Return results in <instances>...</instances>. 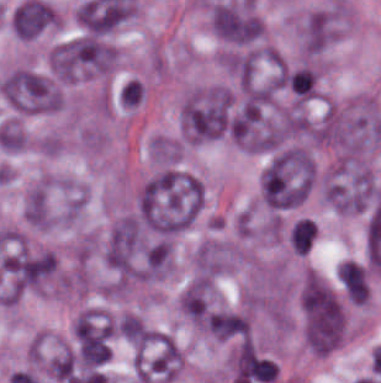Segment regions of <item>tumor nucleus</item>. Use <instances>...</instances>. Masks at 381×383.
Segmentation results:
<instances>
[{"instance_id":"3e47fb67","label":"tumor nucleus","mask_w":381,"mask_h":383,"mask_svg":"<svg viewBox=\"0 0 381 383\" xmlns=\"http://www.w3.org/2000/svg\"><path fill=\"white\" fill-rule=\"evenodd\" d=\"M315 236V224L307 219H300L290 234V246L294 252L303 256L313 243Z\"/></svg>"},{"instance_id":"feef74b5","label":"tumor nucleus","mask_w":381,"mask_h":383,"mask_svg":"<svg viewBox=\"0 0 381 383\" xmlns=\"http://www.w3.org/2000/svg\"><path fill=\"white\" fill-rule=\"evenodd\" d=\"M117 332L136 346H144L152 336L144 324L133 315H126L117 326Z\"/></svg>"},{"instance_id":"3d1891a8","label":"tumor nucleus","mask_w":381,"mask_h":383,"mask_svg":"<svg viewBox=\"0 0 381 383\" xmlns=\"http://www.w3.org/2000/svg\"><path fill=\"white\" fill-rule=\"evenodd\" d=\"M139 240L138 222L125 218L110 233L105 245L106 265L115 271L128 272Z\"/></svg>"},{"instance_id":"2cbd58db","label":"tumor nucleus","mask_w":381,"mask_h":383,"mask_svg":"<svg viewBox=\"0 0 381 383\" xmlns=\"http://www.w3.org/2000/svg\"><path fill=\"white\" fill-rule=\"evenodd\" d=\"M210 22L217 36L237 45L257 41L263 32L257 16L234 4H215Z\"/></svg>"},{"instance_id":"8087334f","label":"tumor nucleus","mask_w":381,"mask_h":383,"mask_svg":"<svg viewBox=\"0 0 381 383\" xmlns=\"http://www.w3.org/2000/svg\"><path fill=\"white\" fill-rule=\"evenodd\" d=\"M249 331V323L241 314L214 312L209 321V334L219 339H238Z\"/></svg>"},{"instance_id":"2083b535","label":"tumor nucleus","mask_w":381,"mask_h":383,"mask_svg":"<svg viewBox=\"0 0 381 383\" xmlns=\"http://www.w3.org/2000/svg\"><path fill=\"white\" fill-rule=\"evenodd\" d=\"M339 282L351 302L365 303L369 285L364 267L358 262L344 261L338 267Z\"/></svg>"},{"instance_id":"2f306a5c","label":"tumor nucleus","mask_w":381,"mask_h":383,"mask_svg":"<svg viewBox=\"0 0 381 383\" xmlns=\"http://www.w3.org/2000/svg\"><path fill=\"white\" fill-rule=\"evenodd\" d=\"M313 180V164L301 149H281L269 156L259 175L262 202L272 209L296 207Z\"/></svg>"},{"instance_id":"5ab6c2c4","label":"tumor nucleus","mask_w":381,"mask_h":383,"mask_svg":"<svg viewBox=\"0 0 381 383\" xmlns=\"http://www.w3.org/2000/svg\"><path fill=\"white\" fill-rule=\"evenodd\" d=\"M0 87L7 101L19 110L44 113L59 107V92L44 76L31 70L15 71Z\"/></svg>"},{"instance_id":"c2bd9aea","label":"tumor nucleus","mask_w":381,"mask_h":383,"mask_svg":"<svg viewBox=\"0 0 381 383\" xmlns=\"http://www.w3.org/2000/svg\"><path fill=\"white\" fill-rule=\"evenodd\" d=\"M331 34V20L324 13H311L302 26L306 51L315 55L325 45Z\"/></svg>"},{"instance_id":"f7901128","label":"tumor nucleus","mask_w":381,"mask_h":383,"mask_svg":"<svg viewBox=\"0 0 381 383\" xmlns=\"http://www.w3.org/2000/svg\"><path fill=\"white\" fill-rule=\"evenodd\" d=\"M50 23L48 22L44 27H42L35 35H33L31 38H34L35 36H37L38 34H40ZM30 38V39H31Z\"/></svg>"},{"instance_id":"8643909e","label":"tumor nucleus","mask_w":381,"mask_h":383,"mask_svg":"<svg viewBox=\"0 0 381 383\" xmlns=\"http://www.w3.org/2000/svg\"><path fill=\"white\" fill-rule=\"evenodd\" d=\"M231 98L223 88H210L188 97L180 127L189 141L213 139L229 131Z\"/></svg>"}]
</instances>
